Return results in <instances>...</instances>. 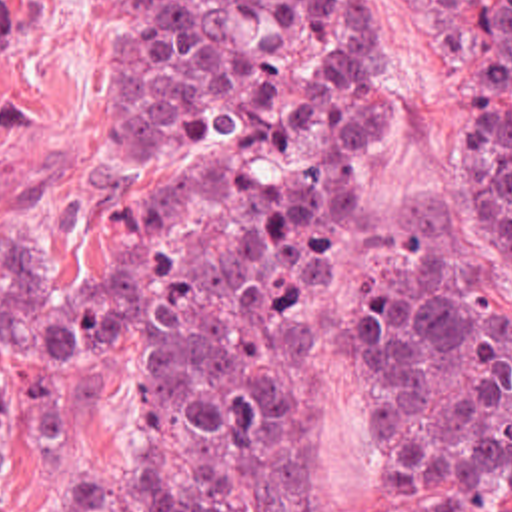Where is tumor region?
Here are the masks:
<instances>
[{"instance_id":"tumor-region-1","label":"tumor region","mask_w":512,"mask_h":512,"mask_svg":"<svg viewBox=\"0 0 512 512\" xmlns=\"http://www.w3.org/2000/svg\"><path fill=\"white\" fill-rule=\"evenodd\" d=\"M475 4L473 163L512 221V0ZM67 36L103 70L99 233L71 249L0 225V345L27 361L59 431L47 473L1 469L61 479L71 429L45 365L121 341L137 455L95 463L61 512H311L303 271L363 114L353 2L0 0V100L31 88ZM359 357L391 463H512V299L481 267L375 263Z\"/></svg>"}]
</instances>
